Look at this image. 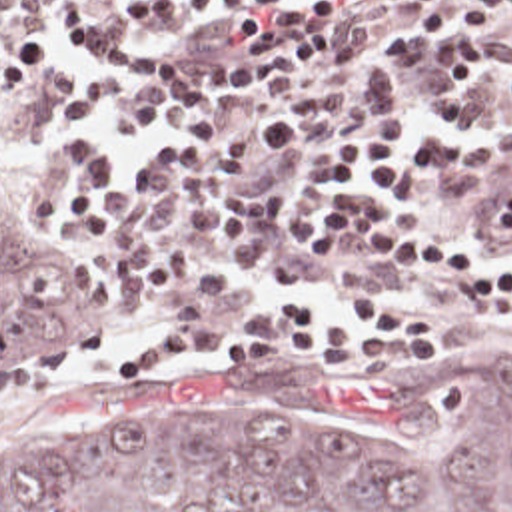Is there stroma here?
Masks as SVG:
<instances>
[{"label":"stroma","mask_w":512,"mask_h":512,"mask_svg":"<svg viewBox=\"0 0 512 512\" xmlns=\"http://www.w3.org/2000/svg\"><path fill=\"white\" fill-rule=\"evenodd\" d=\"M144 0H60L38 31L56 39V61L32 87L0 91V216L42 252L84 268L100 288L102 304L94 316L64 344L16 366L0 368V434H16L50 426L102 420L110 416H168L184 420L250 422L286 400L332 418L338 400L382 384L394 376L441 364L467 360L512 340V316L499 314L491 302L433 274H410L386 262L340 248L334 264L308 282L260 272L232 262L246 276L258 278L254 294L230 316L204 322H176V312L192 300L190 290L158 284L154 306L140 322L120 316V280L100 262V242H74L44 234L36 226V180L48 166L40 160L48 137H80L110 156V180L130 178V164L174 154L172 133L190 121H238L252 139L258 117H298L306 125V150L270 164L258 176L266 180L306 182V220H314L336 192L314 162L316 148L340 139L364 119L402 123L408 142L423 125H437L439 144L483 146L512 139V109L495 113V73H481L471 99L469 125L459 117L435 119L431 95L439 89L437 47L449 33L418 29L416 13L425 11L400 0H340L342 11L334 29L358 33L362 55L324 69L280 93L242 107H172L162 125L144 139H108L104 115L98 111L86 131L64 125V101L82 95L86 73H110L84 43L66 35L60 21L124 23L122 15ZM2 23L18 25V15H0ZM485 33L495 53L512 39V11L469 25ZM156 49L174 57H240V43L214 19H192L170 33L144 35ZM178 93V71H176ZM465 244L499 252L512 262V244H489L483 238L475 204L445 196L420 170L412 196L404 204ZM332 256V244H330ZM384 294L437 314L445 322V354L431 364H374L360 356L340 364L316 358L310 346H288L278 364H236L228 342L252 330V316L292 296H322L352 304ZM202 334V346L176 362L128 378L126 358L164 338Z\"/></svg>","instance_id":"1"}]
</instances>
